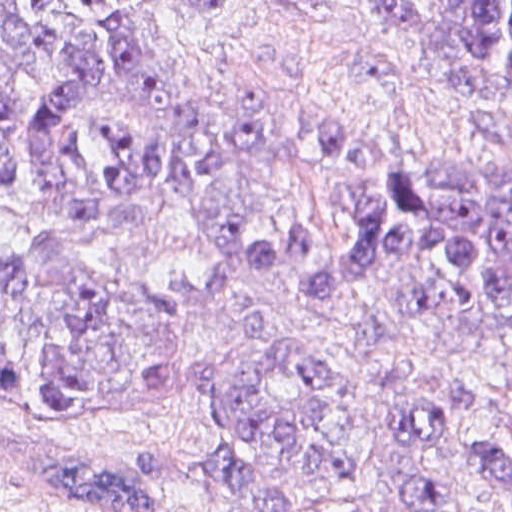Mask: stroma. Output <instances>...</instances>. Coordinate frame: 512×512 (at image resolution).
Listing matches in <instances>:
<instances>
[{
	"mask_svg": "<svg viewBox=\"0 0 512 512\" xmlns=\"http://www.w3.org/2000/svg\"><path fill=\"white\" fill-rule=\"evenodd\" d=\"M185 0H152L158 38L170 63L207 105L260 123L269 132V174L231 287L204 304L185 329L179 387L161 397L84 417L41 410L13 378L0 376V512H90L38 472L46 437H63L105 461L149 479L155 512H255L202 465L210 408L202 356L256 360L264 343L245 331L258 319L285 344L324 347L364 387L350 424L355 480L346 493L303 497L291 512H512V496L489 485L458 449L416 455L394 437L398 408L421 391L457 380L483 385L485 402L465 429L493 441L512 438L510 366L495 333L422 329L371 353L338 333L384 290L379 268L314 300L296 288L308 269L262 272L266 239L301 219L331 242L351 235L349 212L332 196L342 186L372 187L401 155L468 157L512 166V120L503 109L473 113L447 91L409 30L377 17L363 0H230L210 15L188 16ZM438 22L443 0H412ZM319 126H339L377 141L361 164H340L316 150ZM142 219L83 225L44 211L28 195L0 193V242L59 246L104 281L162 288L181 278L205 283L216 240L158 187L144 192Z\"/></svg>",
	"mask_w": 512,
	"mask_h": 512,
	"instance_id": "obj_1",
	"label": "stroma"
}]
</instances>
